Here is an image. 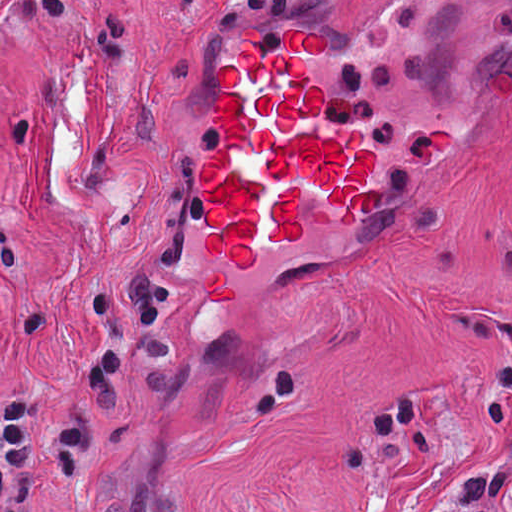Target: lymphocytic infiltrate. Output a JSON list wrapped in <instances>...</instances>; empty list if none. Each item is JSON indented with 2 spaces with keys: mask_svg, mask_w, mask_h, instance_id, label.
I'll list each match as a JSON object with an SVG mask.
<instances>
[{
  "mask_svg": "<svg viewBox=\"0 0 512 512\" xmlns=\"http://www.w3.org/2000/svg\"><path fill=\"white\" fill-rule=\"evenodd\" d=\"M485 375L476 413L486 419L510 416L512 366ZM394 437L425 455L442 446L425 421V394L414 387L378 403L353 427L344 459L350 467L379 473L376 452ZM93 479L94 419L82 399L61 407L42 436L40 406L27 388L0 396V512H39L44 502L82 495ZM511 486L509 466L472 475L463 496L466 512H501Z\"/></svg>",
  "mask_w": 512,
  "mask_h": 512,
  "instance_id": "1",
  "label": "lymphocytic infiltrate"
}]
</instances>
